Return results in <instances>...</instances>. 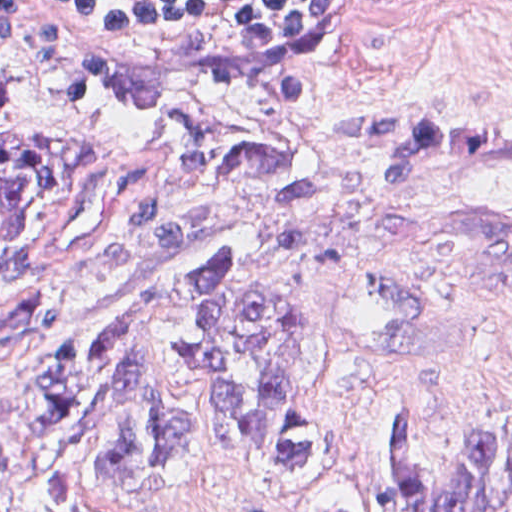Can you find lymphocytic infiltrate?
Here are the masks:
<instances>
[{
	"label": "lymphocytic infiltrate",
	"instance_id": "lymphocytic-infiltrate-1",
	"mask_svg": "<svg viewBox=\"0 0 512 512\" xmlns=\"http://www.w3.org/2000/svg\"><path fill=\"white\" fill-rule=\"evenodd\" d=\"M92 42L170 63L261 71L328 19L337 1H52Z\"/></svg>",
	"mask_w": 512,
	"mask_h": 512
}]
</instances>
